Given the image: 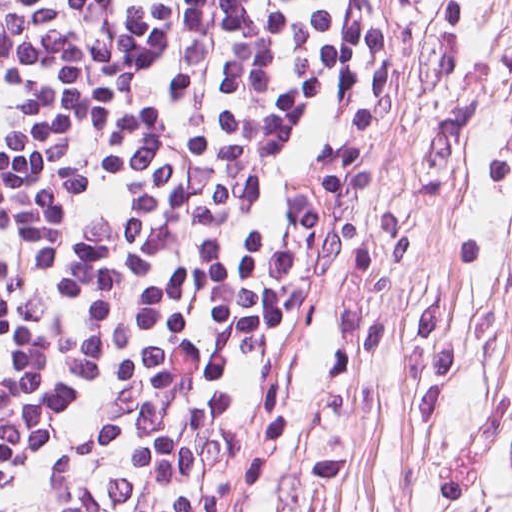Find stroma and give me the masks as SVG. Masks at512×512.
I'll list each match as a JSON object with an SVG mask.
<instances>
[{"label": "stroma", "instance_id": "35a3bbf8", "mask_svg": "<svg viewBox=\"0 0 512 512\" xmlns=\"http://www.w3.org/2000/svg\"><path fill=\"white\" fill-rule=\"evenodd\" d=\"M225 512H512V0H402L365 190Z\"/></svg>", "mask_w": 512, "mask_h": 512}]
</instances>
